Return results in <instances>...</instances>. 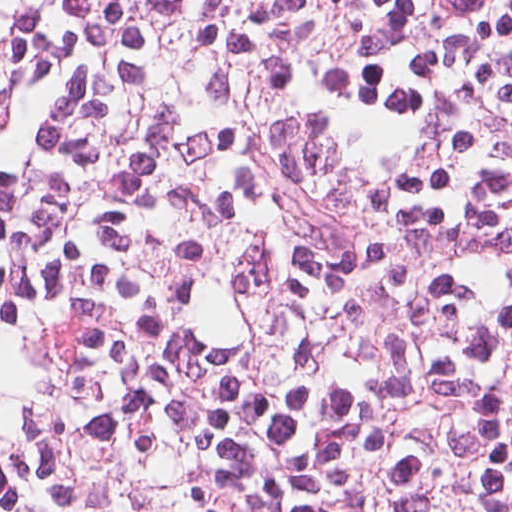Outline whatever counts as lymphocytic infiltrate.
Returning <instances> with one entry per match:
<instances>
[{
	"instance_id": "lymphocytic-infiltrate-1",
	"label": "lymphocytic infiltrate",
	"mask_w": 512,
	"mask_h": 512,
	"mask_svg": "<svg viewBox=\"0 0 512 512\" xmlns=\"http://www.w3.org/2000/svg\"><path fill=\"white\" fill-rule=\"evenodd\" d=\"M0 512H512V0H0Z\"/></svg>"
}]
</instances>
